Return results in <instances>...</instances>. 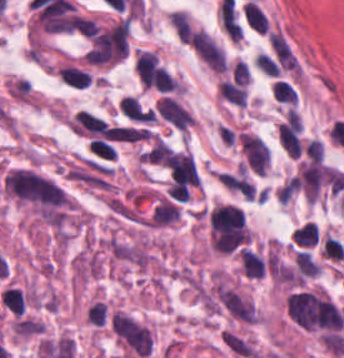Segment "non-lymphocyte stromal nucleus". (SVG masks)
<instances>
[{"label": "non-lymphocyte stromal nucleus", "mask_w": 344, "mask_h": 358, "mask_svg": "<svg viewBox=\"0 0 344 358\" xmlns=\"http://www.w3.org/2000/svg\"><path fill=\"white\" fill-rule=\"evenodd\" d=\"M323 177L322 162L301 160L294 179L307 200L314 203L323 184Z\"/></svg>", "instance_id": "non-lymphocyte-stromal-nucleus-5"}, {"label": "non-lymphocyte stromal nucleus", "mask_w": 344, "mask_h": 358, "mask_svg": "<svg viewBox=\"0 0 344 358\" xmlns=\"http://www.w3.org/2000/svg\"><path fill=\"white\" fill-rule=\"evenodd\" d=\"M253 64L265 74L275 76L273 59L268 53L261 50L254 56Z\"/></svg>", "instance_id": "non-lymphocyte-stromal-nucleus-16"}, {"label": "non-lymphocyte stromal nucleus", "mask_w": 344, "mask_h": 358, "mask_svg": "<svg viewBox=\"0 0 344 358\" xmlns=\"http://www.w3.org/2000/svg\"><path fill=\"white\" fill-rule=\"evenodd\" d=\"M238 141L249 169L257 174L265 173L269 165V147L258 134L240 132Z\"/></svg>", "instance_id": "non-lymphocyte-stromal-nucleus-3"}, {"label": "non-lymphocyte stromal nucleus", "mask_w": 344, "mask_h": 358, "mask_svg": "<svg viewBox=\"0 0 344 358\" xmlns=\"http://www.w3.org/2000/svg\"><path fill=\"white\" fill-rule=\"evenodd\" d=\"M193 51L213 70L222 71L226 66L222 50L205 31L193 30L188 39Z\"/></svg>", "instance_id": "non-lymphocyte-stromal-nucleus-4"}, {"label": "non-lymphocyte stromal nucleus", "mask_w": 344, "mask_h": 358, "mask_svg": "<svg viewBox=\"0 0 344 358\" xmlns=\"http://www.w3.org/2000/svg\"><path fill=\"white\" fill-rule=\"evenodd\" d=\"M271 93L274 99L289 104L294 105L297 100V91L288 81H283L278 79L274 81L271 87Z\"/></svg>", "instance_id": "non-lymphocyte-stromal-nucleus-14"}, {"label": "non-lymphocyte stromal nucleus", "mask_w": 344, "mask_h": 358, "mask_svg": "<svg viewBox=\"0 0 344 358\" xmlns=\"http://www.w3.org/2000/svg\"><path fill=\"white\" fill-rule=\"evenodd\" d=\"M218 20L230 40L236 41L243 35L236 11L233 5L226 0L219 5Z\"/></svg>", "instance_id": "non-lymphocyte-stromal-nucleus-7"}, {"label": "non-lymphocyte stromal nucleus", "mask_w": 344, "mask_h": 358, "mask_svg": "<svg viewBox=\"0 0 344 358\" xmlns=\"http://www.w3.org/2000/svg\"><path fill=\"white\" fill-rule=\"evenodd\" d=\"M294 256L299 274L306 277L319 274V266L308 251L296 249Z\"/></svg>", "instance_id": "non-lymphocyte-stromal-nucleus-13"}, {"label": "non-lymphocyte stromal nucleus", "mask_w": 344, "mask_h": 358, "mask_svg": "<svg viewBox=\"0 0 344 358\" xmlns=\"http://www.w3.org/2000/svg\"><path fill=\"white\" fill-rule=\"evenodd\" d=\"M119 109L125 116L133 120H153L151 109L134 95L128 94L121 98L119 102Z\"/></svg>", "instance_id": "non-lymphocyte-stromal-nucleus-8"}, {"label": "non-lymphocyte stromal nucleus", "mask_w": 344, "mask_h": 358, "mask_svg": "<svg viewBox=\"0 0 344 358\" xmlns=\"http://www.w3.org/2000/svg\"><path fill=\"white\" fill-rule=\"evenodd\" d=\"M180 208L168 199H160L149 216L148 225L160 226L175 221L179 216Z\"/></svg>", "instance_id": "non-lymphocyte-stromal-nucleus-9"}, {"label": "non-lymphocyte stromal nucleus", "mask_w": 344, "mask_h": 358, "mask_svg": "<svg viewBox=\"0 0 344 358\" xmlns=\"http://www.w3.org/2000/svg\"><path fill=\"white\" fill-rule=\"evenodd\" d=\"M56 75L69 86L84 88L89 86L90 76L86 70L70 64L56 66Z\"/></svg>", "instance_id": "non-lymphocyte-stromal-nucleus-10"}, {"label": "non-lymphocyte stromal nucleus", "mask_w": 344, "mask_h": 358, "mask_svg": "<svg viewBox=\"0 0 344 358\" xmlns=\"http://www.w3.org/2000/svg\"><path fill=\"white\" fill-rule=\"evenodd\" d=\"M211 232L218 236H246L244 210L233 203H219L209 216Z\"/></svg>", "instance_id": "non-lymphocyte-stromal-nucleus-2"}, {"label": "non-lymphocyte stromal nucleus", "mask_w": 344, "mask_h": 358, "mask_svg": "<svg viewBox=\"0 0 344 358\" xmlns=\"http://www.w3.org/2000/svg\"><path fill=\"white\" fill-rule=\"evenodd\" d=\"M86 145L99 158L115 159L116 150L113 145L100 137H93Z\"/></svg>", "instance_id": "non-lymphocyte-stromal-nucleus-15"}, {"label": "non-lymphocyte stromal nucleus", "mask_w": 344, "mask_h": 358, "mask_svg": "<svg viewBox=\"0 0 344 358\" xmlns=\"http://www.w3.org/2000/svg\"><path fill=\"white\" fill-rule=\"evenodd\" d=\"M291 238L297 247H314L318 241V228L307 220L295 229Z\"/></svg>", "instance_id": "non-lymphocyte-stromal-nucleus-11"}, {"label": "non-lymphocyte stromal nucleus", "mask_w": 344, "mask_h": 358, "mask_svg": "<svg viewBox=\"0 0 344 358\" xmlns=\"http://www.w3.org/2000/svg\"><path fill=\"white\" fill-rule=\"evenodd\" d=\"M177 38L179 41H187L189 40V36L191 33L189 20L185 11L182 10H174L171 12L168 18Z\"/></svg>", "instance_id": "non-lymphocyte-stromal-nucleus-12"}, {"label": "non-lymphocyte stromal nucleus", "mask_w": 344, "mask_h": 358, "mask_svg": "<svg viewBox=\"0 0 344 358\" xmlns=\"http://www.w3.org/2000/svg\"><path fill=\"white\" fill-rule=\"evenodd\" d=\"M286 309L292 321L304 329L338 330L337 306L320 289L292 292L287 297Z\"/></svg>", "instance_id": "non-lymphocyte-stromal-nucleus-1"}, {"label": "non-lymphocyte stromal nucleus", "mask_w": 344, "mask_h": 358, "mask_svg": "<svg viewBox=\"0 0 344 358\" xmlns=\"http://www.w3.org/2000/svg\"><path fill=\"white\" fill-rule=\"evenodd\" d=\"M154 111L178 129L186 130L193 119L190 111L175 97L162 94Z\"/></svg>", "instance_id": "non-lymphocyte-stromal-nucleus-6"}, {"label": "non-lymphocyte stromal nucleus", "mask_w": 344, "mask_h": 358, "mask_svg": "<svg viewBox=\"0 0 344 358\" xmlns=\"http://www.w3.org/2000/svg\"><path fill=\"white\" fill-rule=\"evenodd\" d=\"M307 158L314 161H322L323 146L322 142L317 138H309L303 148Z\"/></svg>", "instance_id": "non-lymphocyte-stromal-nucleus-17"}]
</instances>
